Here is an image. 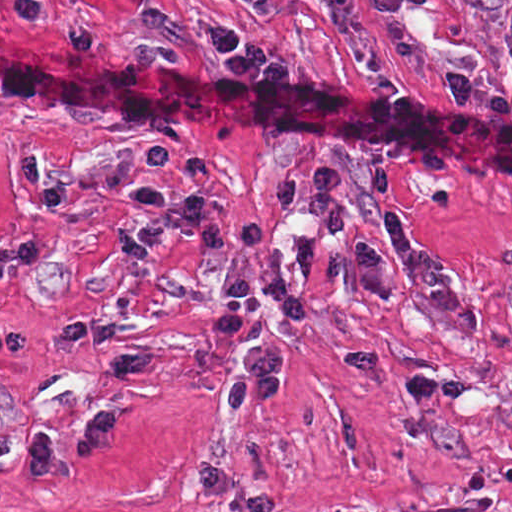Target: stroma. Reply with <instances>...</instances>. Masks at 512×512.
Returning a JSON list of instances; mask_svg holds the SVG:
<instances>
[{
	"label": "stroma",
	"mask_w": 512,
	"mask_h": 512,
	"mask_svg": "<svg viewBox=\"0 0 512 512\" xmlns=\"http://www.w3.org/2000/svg\"><path fill=\"white\" fill-rule=\"evenodd\" d=\"M376 35L372 0H357ZM246 29L283 74H228L202 36ZM405 24L473 81L472 105L392 57L365 67L314 0H0V512H512V187L383 137L228 107L114 112L1 89V30L216 90L321 92L475 115L512 129V0H426ZM335 167L348 228L325 237L272 206L269 179ZM388 170L414 232L439 246L486 321L463 338L414 282L395 301L330 275L296 320L265 297L286 347L279 404L226 418L248 335L209 327L223 269L166 229L145 250L127 192L203 193L234 231L259 217L285 273L391 241Z\"/></svg>",
	"instance_id": "stroma-1"
}]
</instances>
